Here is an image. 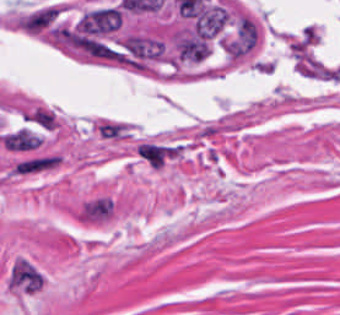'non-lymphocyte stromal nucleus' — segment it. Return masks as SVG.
Wrapping results in <instances>:
<instances>
[{
	"label": "non-lymphocyte stromal nucleus",
	"mask_w": 340,
	"mask_h": 315,
	"mask_svg": "<svg viewBox=\"0 0 340 315\" xmlns=\"http://www.w3.org/2000/svg\"><path fill=\"white\" fill-rule=\"evenodd\" d=\"M60 158L55 153H30L17 158L11 176H33L56 168Z\"/></svg>",
	"instance_id": "obj_1"
}]
</instances>
